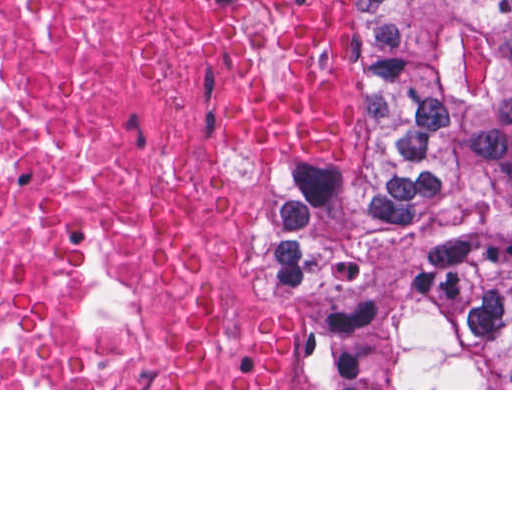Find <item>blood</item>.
<instances>
[{
    "label": "blood",
    "instance_id": "1",
    "mask_svg": "<svg viewBox=\"0 0 512 512\" xmlns=\"http://www.w3.org/2000/svg\"><path fill=\"white\" fill-rule=\"evenodd\" d=\"M228 135L295 160H335L363 128L350 38L311 0H276L267 33L237 56L217 101ZM294 344L234 271L202 283L172 316L156 388H292Z\"/></svg>",
    "mask_w": 512,
    "mask_h": 512
}]
</instances>
